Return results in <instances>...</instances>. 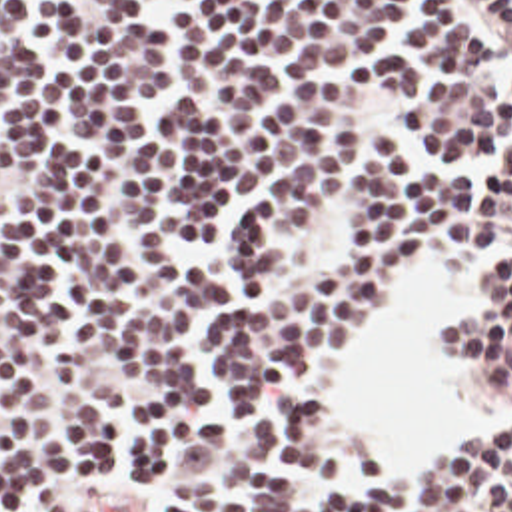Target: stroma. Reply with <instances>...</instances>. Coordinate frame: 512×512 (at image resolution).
Masks as SVG:
<instances>
[{
	"label": "stroma",
	"instance_id": "1",
	"mask_svg": "<svg viewBox=\"0 0 512 512\" xmlns=\"http://www.w3.org/2000/svg\"><path fill=\"white\" fill-rule=\"evenodd\" d=\"M424 259L432 261V259H430V257H426V255H424ZM471 263H473V275H475V279H491V277L511 275L512 235L511 237H507V239H503V241H501V243H497V245L485 247V249L477 251L475 255H471ZM408 285H410V283H408ZM386 323H388V321H386ZM386 323H384V327H382V331H380V335H378V339H376V343H374V347H372V351H370L368 359L362 363V367H360L354 375H350L346 381H342V383H338L336 387H332V391H330L328 405H330V413H332V417H334V421H336L338 433H340V435H344V437L352 443V447H354L356 451L370 453V455H388V453L408 451V449H420V447H448V445H459V443H467V441L479 439V437H465V439H459V441L446 439V441H434V443H408V445H396V447H366V445H362V443L358 441V437H356L352 431H348V429L342 425V421L338 419V413H336V405H338V401H340V397H342L344 393H348L356 383H360V381H362V377H364L366 369H368V367L372 365V361L376 359L378 345H380V341H382V337H384V331H386ZM428 347H430V355H432V359H434V363H436V367H438V371H440L438 353H436V331H428ZM440 375H442V371H440ZM442 379H444V377H442ZM444 385H446V389H448V393H450L452 401L461 399V397L457 395L456 391H454L446 381H444ZM501 433H505V431H501ZM495 435H497V433H495Z\"/></svg>",
	"mask_w": 512,
	"mask_h": 512
}]
</instances>
